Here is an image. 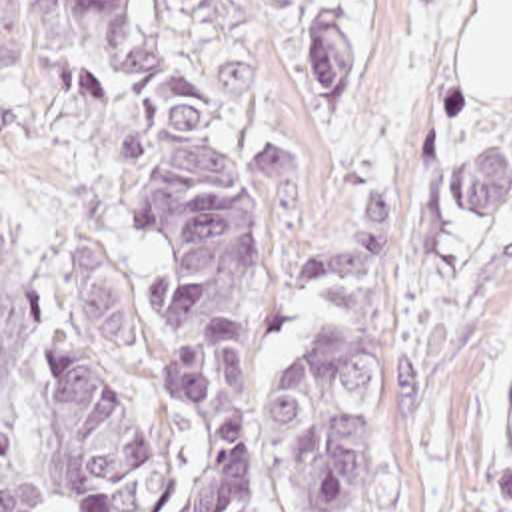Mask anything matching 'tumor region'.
<instances>
[{"label": "tumor region", "instance_id": "tumor-region-1", "mask_svg": "<svg viewBox=\"0 0 512 512\" xmlns=\"http://www.w3.org/2000/svg\"><path fill=\"white\" fill-rule=\"evenodd\" d=\"M313 43V113L327 119L333 97L353 75L347 21L321 15L307 27ZM270 249L297 203L291 127L277 119L258 133ZM511 187V157L473 147L451 163L447 201L459 217H481ZM327 285L343 301L337 325L315 335L283 377L297 512H349L355 460L385 387V189L371 179V211L339 245L305 261L273 295ZM501 512H512V385L499 445Z\"/></svg>", "mask_w": 512, "mask_h": 512}]
</instances>
